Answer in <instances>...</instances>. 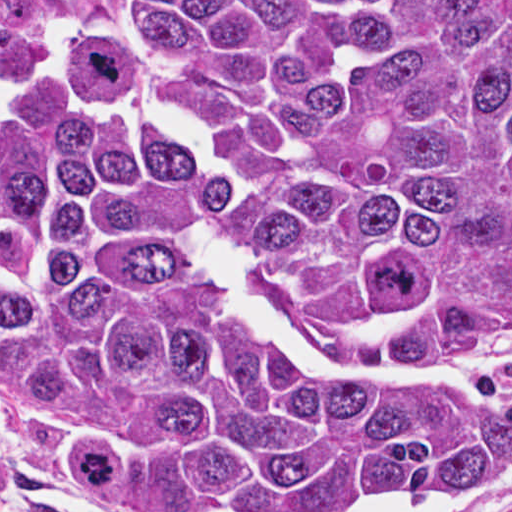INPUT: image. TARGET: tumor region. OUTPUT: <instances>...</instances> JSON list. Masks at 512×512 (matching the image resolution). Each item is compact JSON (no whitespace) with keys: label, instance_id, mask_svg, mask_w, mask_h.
<instances>
[{"label":"tumor region","instance_id":"tumor-region-1","mask_svg":"<svg viewBox=\"0 0 512 512\" xmlns=\"http://www.w3.org/2000/svg\"><path fill=\"white\" fill-rule=\"evenodd\" d=\"M132 109L103 102L123 82ZM211 224L315 337L512 342V0H124L0 33L7 424L141 512L512 470L474 389L296 372L185 253Z\"/></svg>","mask_w":512,"mask_h":512}]
</instances>
